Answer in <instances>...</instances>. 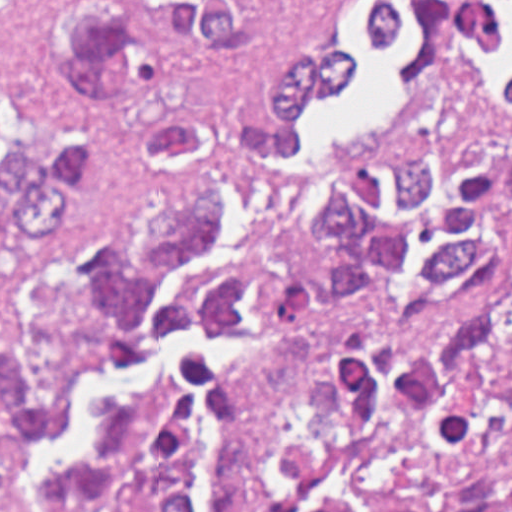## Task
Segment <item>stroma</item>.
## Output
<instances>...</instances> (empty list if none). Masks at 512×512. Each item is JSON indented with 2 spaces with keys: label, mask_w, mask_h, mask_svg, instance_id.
Instances as JSON below:
<instances>
[{
  "label": "stroma",
  "mask_w": 512,
  "mask_h": 512,
  "mask_svg": "<svg viewBox=\"0 0 512 512\" xmlns=\"http://www.w3.org/2000/svg\"><path fill=\"white\" fill-rule=\"evenodd\" d=\"M39 1H261V21L256 39L220 58L178 46L168 59L167 82L203 112L211 131L187 147L151 157L135 141L120 101L101 97L89 200L67 224L22 246L14 267L0 269V346L21 329L25 289L48 254L128 232L147 215L206 184L223 167L232 151L235 92L247 70L283 45H335L326 18L342 1H371L363 13V35L373 47L404 34L393 1H412L413 17L415 11L423 15V45L399 63L402 94L373 137L329 144L295 185L277 195L275 209L256 227L241 262L219 266L207 278L249 274L258 294L293 238L290 206L311 178L363 170L400 142L512 134V71L505 73L507 106H495L486 74L461 45L465 35L473 53L493 50L497 39L490 1L512 0H0V61L19 74L29 93L61 124L80 113V93L39 32ZM262 1H271V13ZM342 395L315 360V338L261 328V389L233 512H252L265 484L268 442L279 423L304 422L324 434L339 416Z\"/></svg>",
  "instance_id": "stroma-1"
}]
</instances>
